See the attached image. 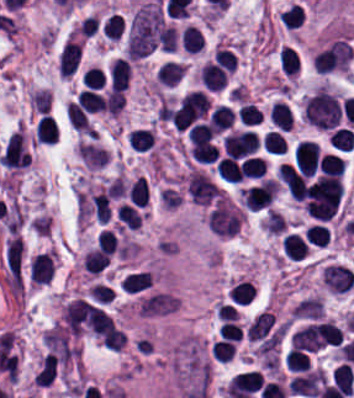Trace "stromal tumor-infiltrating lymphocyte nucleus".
<instances>
[{"label":"stromal tumor-infiltrating lymphocyte nucleus","instance_id":"obj_28","mask_svg":"<svg viewBox=\"0 0 354 398\" xmlns=\"http://www.w3.org/2000/svg\"><path fill=\"white\" fill-rule=\"evenodd\" d=\"M78 99L81 105L92 113L103 109V97L96 91L84 89L79 92Z\"/></svg>","mask_w":354,"mask_h":398},{"label":"stromal tumor-infiltrating lymphocyte nucleus","instance_id":"obj_2","mask_svg":"<svg viewBox=\"0 0 354 398\" xmlns=\"http://www.w3.org/2000/svg\"><path fill=\"white\" fill-rule=\"evenodd\" d=\"M96 306L82 297H75L63 308L62 316L65 328L74 334H80L93 321Z\"/></svg>","mask_w":354,"mask_h":398},{"label":"stromal tumor-infiltrating lymphocyte nucleus","instance_id":"obj_10","mask_svg":"<svg viewBox=\"0 0 354 398\" xmlns=\"http://www.w3.org/2000/svg\"><path fill=\"white\" fill-rule=\"evenodd\" d=\"M306 245L305 240L295 232H287L281 237L282 254L290 260H299Z\"/></svg>","mask_w":354,"mask_h":398},{"label":"stromal tumor-infiltrating lymphocyte nucleus","instance_id":"obj_5","mask_svg":"<svg viewBox=\"0 0 354 398\" xmlns=\"http://www.w3.org/2000/svg\"><path fill=\"white\" fill-rule=\"evenodd\" d=\"M81 55V41L68 38L58 56V72L70 76L77 68Z\"/></svg>","mask_w":354,"mask_h":398},{"label":"stromal tumor-infiltrating lymphocyte nucleus","instance_id":"obj_23","mask_svg":"<svg viewBox=\"0 0 354 398\" xmlns=\"http://www.w3.org/2000/svg\"><path fill=\"white\" fill-rule=\"evenodd\" d=\"M104 109L111 116H117L124 105V97L121 91L109 89L102 99Z\"/></svg>","mask_w":354,"mask_h":398},{"label":"stromal tumor-infiltrating lymphocyte nucleus","instance_id":"obj_15","mask_svg":"<svg viewBox=\"0 0 354 398\" xmlns=\"http://www.w3.org/2000/svg\"><path fill=\"white\" fill-rule=\"evenodd\" d=\"M208 119L211 128L219 132L232 124L234 115L233 111L228 106L219 104L211 110Z\"/></svg>","mask_w":354,"mask_h":398},{"label":"stromal tumor-infiltrating lymphocyte nucleus","instance_id":"obj_27","mask_svg":"<svg viewBox=\"0 0 354 398\" xmlns=\"http://www.w3.org/2000/svg\"><path fill=\"white\" fill-rule=\"evenodd\" d=\"M177 33L174 26H160L157 32L159 48L164 52H174L176 46Z\"/></svg>","mask_w":354,"mask_h":398},{"label":"stromal tumor-infiltrating lymphocyte nucleus","instance_id":"obj_1","mask_svg":"<svg viewBox=\"0 0 354 398\" xmlns=\"http://www.w3.org/2000/svg\"><path fill=\"white\" fill-rule=\"evenodd\" d=\"M241 211L232 201L218 199L207 213V226L219 237H232L238 232Z\"/></svg>","mask_w":354,"mask_h":398},{"label":"stromal tumor-infiltrating lymphocyte nucleus","instance_id":"obj_26","mask_svg":"<svg viewBox=\"0 0 354 398\" xmlns=\"http://www.w3.org/2000/svg\"><path fill=\"white\" fill-rule=\"evenodd\" d=\"M234 349L235 346L229 339H216L210 347L212 358L224 362L232 360Z\"/></svg>","mask_w":354,"mask_h":398},{"label":"stromal tumor-infiltrating lymphocyte nucleus","instance_id":"obj_30","mask_svg":"<svg viewBox=\"0 0 354 398\" xmlns=\"http://www.w3.org/2000/svg\"><path fill=\"white\" fill-rule=\"evenodd\" d=\"M327 237L328 231L319 223H312L306 228L305 239L311 244L325 246Z\"/></svg>","mask_w":354,"mask_h":398},{"label":"stromal tumor-infiltrating lymphocyte nucleus","instance_id":"obj_13","mask_svg":"<svg viewBox=\"0 0 354 398\" xmlns=\"http://www.w3.org/2000/svg\"><path fill=\"white\" fill-rule=\"evenodd\" d=\"M277 57L284 75L293 76L299 62L295 48L290 44H282Z\"/></svg>","mask_w":354,"mask_h":398},{"label":"stromal tumor-infiltrating lymphocyte nucleus","instance_id":"obj_21","mask_svg":"<svg viewBox=\"0 0 354 398\" xmlns=\"http://www.w3.org/2000/svg\"><path fill=\"white\" fill-rule=\"evenodd\" d=\"M329 144L339 149H353L354 133L348 128H334L328 138Z\"/></svg>","mask_w":354,"mask_h":398},{"label":"stromal tumor-infiltrating lymphocyte nucleus","instance_id":"obj_7","mask_svg":"<svg viewBox=\"0 0 354 398\" xmlns=\"http://www.w3.org/2000/svg\"><path fill=\"white\" fill-rule=\"evenodd\" d=\"M130 64L127 59L115 57L108 69L112 89L124 90L128 86Z\"/></svg>","mask_w":354,"mask_h":398},{"label":"stromal tumor-infiltrating lymphocyte nucleus","instance_id":"obj_9","mask_svg":"<svg viewBox=\"0 0 354 398\" xmlns=\"http://www.w3.org/2000/svg\"><path fill=\"white\" fill-rule=\"evenodd\" d=\"M314 335L318 345H334L338 344L343 331L329 321L313 323Z\"/></svg>","mask_w":354,"mask_h":398},{"label":"stromal tumor-infiltrating lymphocyte nucleus","instance_id":"obj_19","mask_svg":"<svg viewBox=\"0 0 354 398\" xmlns=\"http://www.w3.org/2000/svg\"><path fill=\"white\" fill-rule=\"evenodd\" d=\"M127 143L134 150H146L151 147L153 143V136L149 129L132 128L128 131Z\"/></svg>","mask_w":354,"mask_h":398},{"label":"stromal tumor-infiltrating lymphocyte nucleus","instance_id":"obj_24","mask_svg":"<svg viewBox=\"0 0 354 398\" xmlns=\"http://www.w3.org/2000/svg\"><path fill=\"white\" fill-rule=\"evenodd\" d=\"M284 362L290 371L297 372L307 369L309 359L305 352L292 347L286 353Z\"/></svg>","mask_w":354,"mask_h":398},{"label":"stromal tumor-infiltrating lymphocyte nucleus","instance_id":"obj_17","mask_svg":"<svg viewBox=\"0 0 354 398\" xmlns=\"http://www.w3.org/2000/svg\"><path fill=\"white\" fill-rule=\"evenodd\" d=\"M216 172L222 179L240 181V171L237 160L230 155H223L216 162Z\"/></svg>","mask_w":354,"mask_h":398},{"label":"stromal tumor-infiltrating lymphocyte nucleus","instance_id":"obj_32","mask_svg":"<svg viewBox=\"0 0 354 398\" xmlns=\"http://www.w3.org/2000/svg\"><path fill=\"white\" fill-rule=\"evenodd\" d=\"M116 247L117 242L114 234L108 229H101L96 240V248L111 255L116 251Z\"/></svg>","mask_w":354,"mask_h":398},{"label":"stromal tumor-infiltrating lymphocyte nucleus","instance_id":"obj_6","mask_svg":"<svg viewBox=\"0 0 354 398\" xmlns=\"http://www.w3.org/2000/svg\"><path fill=\"white\" fill-rule=\"evenodd\" d=\"M254 296L253 280L241 276L231 284L228 290V298L240 306L251 302Z\"/></svg>","mask_w":354,"mask_h":398},{"label":"stromal tumor-infiltrating lymphocyte nucleus","instance_id":"obj_31","mask_svg":"<svg viewBox=\"0 0 354 398\" xmlns=\"http://www.w3.org/2000/svg\"><path fill=\"white\" fill-rule=\"evenodd\" d=\"M29 99L34 111L48 113L50 106V90L48 88L39 89L31 94Z\"/></svg>","mask_w":354,"mask_h":398},{"label":"stromal tumor-infiltrating lymphocyte nucleus","instance_id":"obj_18","mask_svg":"<svg viewBox=\"0 0 354 398\" xmlns=\"http://www.w3.org/2000/svg\"><path fill=\"white\" fill-rule=\"evenodd\" d=\"M239 172L242 176L260 177L265 172V163L260 155H247L240 159Z\"/></svg>","mask_w":354,"mask_h":398},{"label":"stromal tumor-infiltrating lymphocyte nucleus","instance_id":"obj_25","mask_svg":"<svg viewBox=\"0 0 354 398\" xmlns=\"http://www.w3.org/2000/svg\"><path fill=\"white\" fill-rule=\"evenodd\" d=\"M124 341L125 336L121 329L111 323L103 333L101 344L111 350L118 351L122 348Z\"/></svg>","mask_w":354,"mask_h":398},{"label":"stromal tumor-infiltrating lymphocyte nucleus","instance_id":"obj_33","mask_svg":"<svg viewBox=\"0 0 354 398\" xmlns=\"http://www.w3.org/2000/svg\"><path fill=\"white\" fill-rule=\"evenodd\" d=\"M241 332L240 324L233 320H226L222 323L218 330L219 338L236 340L239 338Z\"/></svg>","mask_w":354,"mask_h":398},{"label":"stromal tumor-infiltrating lymphocyte nucleus","instance_id":"obj_20","mask_svg":"<svg viewBox=\"0 0 354 398\" xmlns=\"http://www.w3.org/2000/svg\"><path fill=\"white\" fill-rule=\"evenodd\" d=\"M108 258L95 248L87 252L81 262L85 271L89 274H98L107 264Z\"/></svg>","mask_w":354,"mask_h":398},{"label":"stromal tumor-infiltrating lymphocyte nucleus","instance_id":"obj_14","mask_svg":"<svg viewBox=\"0 0 354 398\" xmlns=\"http://www.w3.org/2000/svg\"><path fill=\"white\" fill-rule=\"evenodd\" d=\"M181 45L187 52H196L203 47L202 32L198 27L186 24L181 30Z\"/></svg>","mask_w":354,"mask_h":398},{"label":"stromal tumor-infiltrating lymphocyte nucleus","instance_id":"obj_8","mask_svg":"<svg viewBox=\"0 0 354 398\" xmlns=\"http://www.w3.org/2000/svg\"><path fill=\"white\" fill-rule=\"evenodd\" d=\"M58 135V127L52 115L42 113L34 129V140L38 143L53 144Z\"/></svg>","mask_w":354,"mask_h":398},{"label":"stromal tumor-infiltrating lymphocyte nucleus","instance_id":"obj_3","mask_svg":"<svg viewBox=\"0 0 354 398\" xmlns=\"http://www.w3.org/2000/svg\"><path fill=\"white\" fill-rule=\"evenodd\" d=\"M295 164L308 176L318 168L319 148L317 143L302 139L294 148Z\"/></svg>","mask_w":354,"mask_h":398},{"label":"stromal tumor-infiltrating lymphocyte nucleus","instance_id":"obj_22","mask_svg":"<svg viewBox=\"0 0 354 398\" xmlns=\"http://www.w3.org/2000/svg\"><path fill=\"white\" fill-rule=\"evenodd\" d=\"M317 164L322 174H341L344 167L341 159L332 152H324Z\"/></svg>","mask_w":354,"mask_h":398},{"label":"stromal tumor-infiltrating lymphocyte nucleus","instance_id":"obj_12","mask_svg":"<svg viewBox=\"0 0 354 398\" xmlns=\"http://www.w3.org/2000/svg\"><path fill=\"white\" fill-rule=\"evenodd\" d=\"M150 281L149 270H136L124 274L121 286L124 291L137 292L148 287Z\"/></svg>","mask_w":354,"mask_h":398},{"label":"stromal tumor-infiltrating lymphocyte nucleus","instance_id":"obj_16","mask_svg":"<svg viewBox=\"0 0 354 398\" xmlns=\"http://www.w3.org/2000/svg\"><path fill=\"white\" fill-rule=\"evenodd\" d=\"M199 79L207 89L211 90H219L227 81L225 73L203 64L199 69Z\"/></svg>","mask_w":354,"mask_h":398},{"label":"stromal tumor-infiltrating lymphocyte nucleus","instance_id":"obj_29","mask_svg":"<svg viewBox=\"0 0 354 398\" xmlns=\"http://www.w3.org/2000/svg\"><path fill=\"white\" fill-rule=\"evenodd\" d=\"M266 153L282 154L286 149L283 137L275 130L268 129L263 136Z\"/></svg>","mask_w":354,"mask_h":398},{"label":"stromal tumor-infiltrating lymphocyte nucleus","instance_id":"obj_4","mask_svg":"<svg viewBox=\"0 0 354 398\" xmlns=\"http://www.w3.org/2000/svg\"><path fill=\"white\" fill-rule=\"evenodd\" d=\"M55 268L54 252L45 251L33 256L29 264V279L32 283L42 284L51 280Z\"/></svg>","mask_w":354,"mask_h":398},{"label":"stromal tumor-infiltrating lymphocyte nucleus","instance_id":"obj_11","mask_svg":"<svg viewBox=\"0 0 354 398\" xmlns=\"http://www.w3.org/2000/svg\"><path fill=\"white\" fill-rule=\"evenodd\" d=\"M185 71V65L172 60H165L157 69V77L166 85H175Z\"/></svg>","mask_w":354,"mask_h":398}]
</instances>
